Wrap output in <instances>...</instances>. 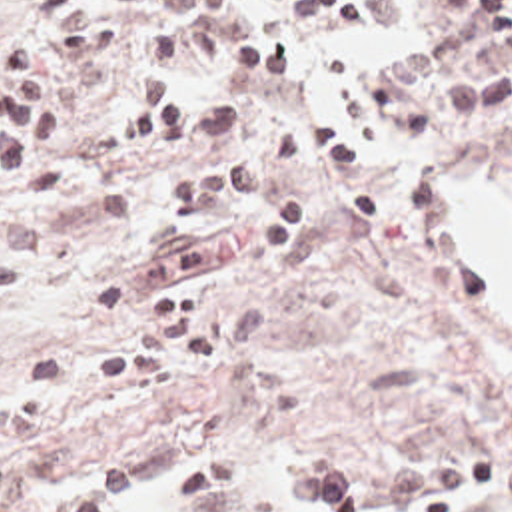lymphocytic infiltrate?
I'll return each instance as SVG.
<instances>
[{"label": "lymphocytic infiltrate", "mask_w": 512, "mask_h": 512, "mask_svg": "<svg viewBox=\"0 0 512 512\" xmlns=\"http://www.w3.org/2000/svg\"><path fill=\"white\" fill-rule=\"evenodd\" d=\"M294 17L340 41L364 31V0H286ZM23 21L0 47V192L44 202L72 168L62 131L48 121V91L32 71L72 59L146 67L130 81L118 113V146L154 166L188 164L158 188L162 214H208L238 202L250 210V248L268 262L292 254L306 234L304 180L344 176L356 141L326 119L288 121L264 160L244 137V107L228 91H196L178 73L190 59L206 73L256 89L284 85L298 51L278 31L256 25L250 0H0V31ZM512 101V0H456L452 29L396 53L366 73L364 111L374 139L416 148L442 127H464ZM438 117L434 121L428 113ZM23 288V260L0 256V302ZM492 460H446L394 468L364 496L336 468L290 472L300 512H476L502 490Z\"/></svg>", "instance_id": "obj_1"}]
</instances>
